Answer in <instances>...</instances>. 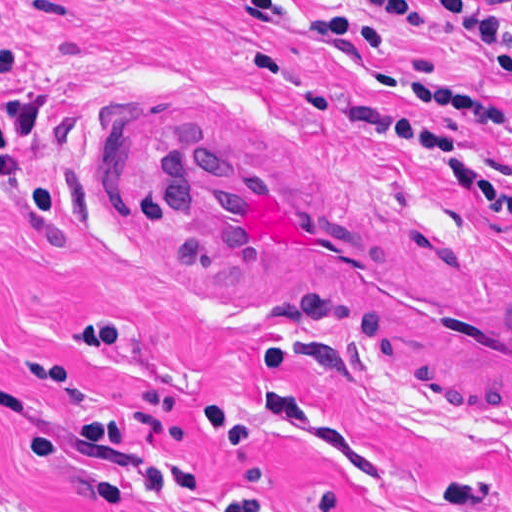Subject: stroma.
<instances>
[{"label": "stroma", "mask_w": 512, "mask_h": 512, "mask_svg": "<svg viewBox=\"0 0 512 512\" xmlns=\"http://www.w3.org/2000/svg\"><path fill=\"white\" fill-rule=\"evenodd\" d=\"M284 1L394 51L302 49L216 0H0V477L45 512H512V424L386 387L295 313L184 291L115 177L110 142L227 105L512 257V213L417 132L334 116L472 126L409 86L506 110L467 163L512 189V82L360 0Z\"/></svg>", "instance_id": "obj_1"}]
</instances>
